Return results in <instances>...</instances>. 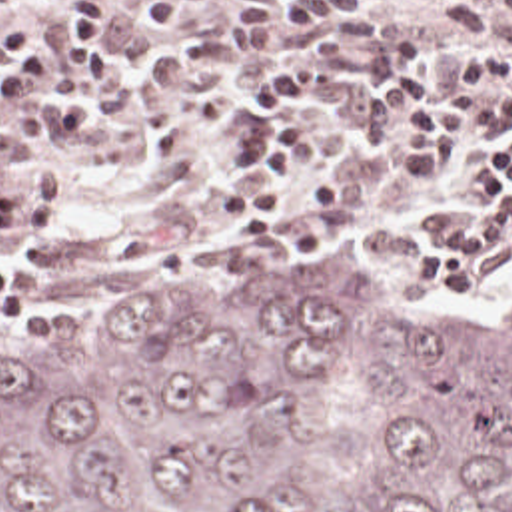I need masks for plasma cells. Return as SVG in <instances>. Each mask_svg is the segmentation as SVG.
<instances>
[{
    "label": "plasma cells",
    "mask_w": 512,
    "mask_h": 512,
    "mask_svg": "<svg viewBox=\"0 0 512 512\" xmlns=\"http://www.w3.org/2000/svg\"><path fill=\"white\" fill-rule=\"evenodd\" d=\"M512 25V0H445L381 13L351 0H233V25L177 43L171 59L149 55L141 95L161 158H187L205 121L231 127L241 101L237 75L261 59L317 61L345 89L385 83L435 57L467 59ZM57 162L35 160L21 141L0 139V244L55 236Z\"/></svg>",
    "instance_id": "plasma-cells-1"
}]
</instances>
